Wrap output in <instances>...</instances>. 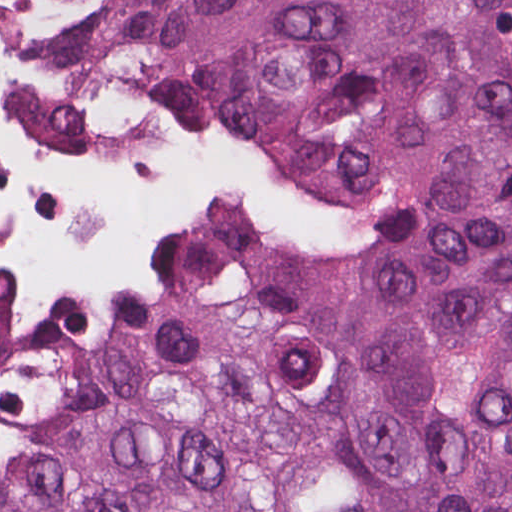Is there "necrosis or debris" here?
I'll return each mask as SVG.
<instances>
[{"mask_svg":"<svg viewBox=\"0 0 512 512\" xmlns=\"http://www.w3.org/2000/svg\"><path fill=\"white\" fill-rule=\"evenodd\" d=\"M321 214L129 88L80 11L0 5V328L116 287L147 248L241 268L261 232L316 229ZM28 462L0 422V483Z\"/></svg>","mask_w":512,"mask_h":512,"instance_id":"obj_1","label":"necrosis or debris"}]
</instances>
